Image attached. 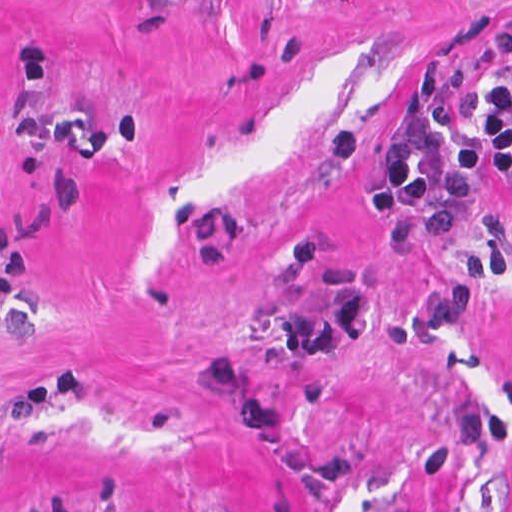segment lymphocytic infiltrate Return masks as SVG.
<instances>
[{"instance_id":"f902f5d3","label":"lymphocytic infiltrate","mask_w":512,"mask_h":512,"mask_svg":"<svg viewBox=\"0 0 512 512\" xmlns=\"http://www.w3.org/2000/svg\"><path fill=\"white\" fill-rule=\"evenodd\" d=\"M482 178L512 187V80L504 77H492L482 92L480 124L457 152L433 166L409 142L395 141L356 200L369 218H405L429 238H447ZM147 512L169 510L154 505Z\"/></svg>"}]
</instances>
